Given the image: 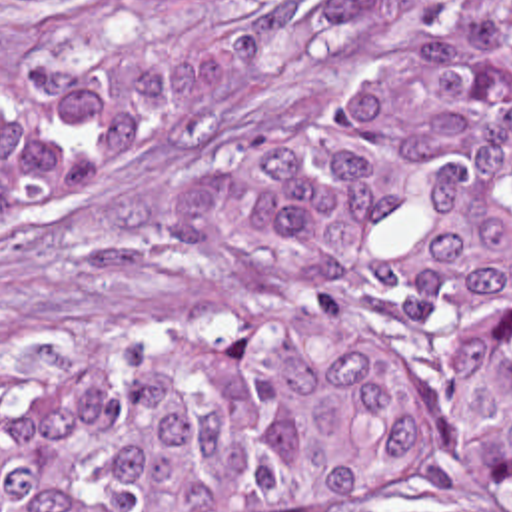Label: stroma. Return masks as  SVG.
Listing matches in <instances>:
<instances>
[{"label": "stroma", "mask_w": 512, "mask_h": 512, "mask_svg": "<svg viewBox=\"0 0 512 512\" xmlns=\"http://www.w3.org/2000/svg\"><path fill=\"white\" fill-rule=\"evenodd\" d=\"M512 0H0V102L66 46L233 42L210 122L92 156L0 224V390L271 300L267 160ZM261 512H512L441 487H325Z\"/></svg>", "instance_id": "obj_1"}]
</instances>
